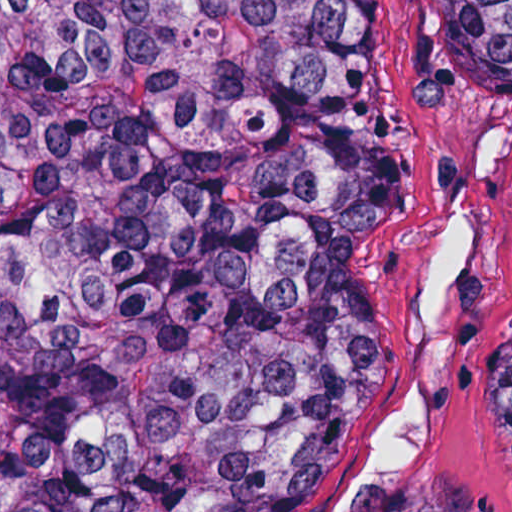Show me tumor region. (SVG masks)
<instances>
[{"label": "tumor region", "instance_id": "1", "mask_svg": "<svg viewBox=\"0 0 512 512\" xmlns=\"http://www.w3.org/2000/svg\"><path fill=\"white\" fill-rule=\"evenodd\" d=\"M512 93V0H445ZM360 0H0V512H291L388 389L402 190ZM512 470V324L486 353Z\"/></svg>", "mask_w": 512, "mask_h": 512}]
</instances>
